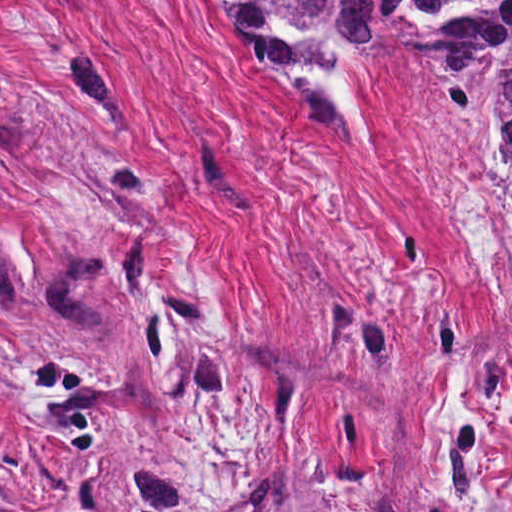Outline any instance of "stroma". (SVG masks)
<instances>
[{
	"label": "stroma",
	"instance_id": "stroma-1",
	"mask_svg": "<svg viewBox=\"0 0 512 512\" xmlns=\"http://www.w3.org/2000/svg\"><path fill=\"white\" fill-rule=\"evenodd\" d=\"M254 65L206 0H0V512H512V327L410 14ZM473 157L471 155H468Z\"/></svg>",
	"mask_w": 512,
	"mask_h": 512
}]
</instances>
